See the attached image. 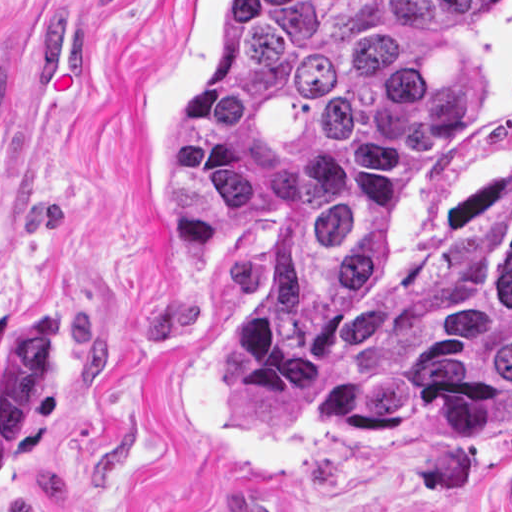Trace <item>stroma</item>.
I'll list each match as a JSON object with an SVG mask.
<instances>
[{
    "instance_id": "obj_1",
    "label": "stroma",
    "mask_w": 512,
    "mask_h": 512,
    "mask_svg": "<svg viewBox=\"0 0 512 512\" xmlns=\"http://www.w3.org/2000/svg\"><path fill=\"white\" fill-rule=\"evenodd\" d=\"M223 1L0 0V512H512V405L454 437L221 415L214 309L266 249L166 262L159 139ZM452 73L466 105L395 175L378 279L512 212V0Z\"/></svg>"
}]
</instances>
